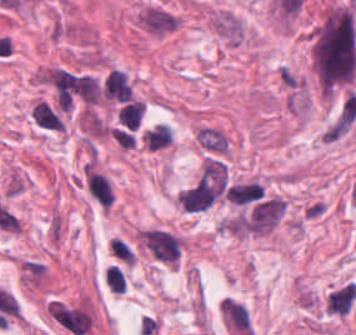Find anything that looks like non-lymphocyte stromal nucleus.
<instances>
[{"label":"non-lymphocyte stromal nucleus","instance_id":"obj_1","mask_svg":"<svg viewBox=\"0 0 356 335\" xmlns=\"http://www.w3.org/2000/svg\"><path fill=\"white\" fill-rule=\"evenodd\" d=\"M228 187L223 161L209 158L183 189L179 203L186 212H203L212 207Z\"/></svg>","mask_w":356,"mask_h":335},{"label":"non-lymphocyte stromal nucleus","instance_id":"obj_2","mask_svg":"<svg viewBox=\"0 0 356 335\" xmlns=\"http://www.w3.org/2000/svg\"><path fill=\"white\" fill-rule=\"evenodd\" d=\"M137 21L139 28L162 38L178 29L182 19L177 12L159 3H145L138 10Z\"/></svg>","mask_w":356,"mask_h":335},{"label":"non-lymphocyte stromal nucleus","instance_id":"obj_3","mask_svg":"<svg viewBox=\"0 0 356 335\" xmlns=\"http://www.w3.org/2000/svg\"><path fill=\"white\" fill-rule=\"evenodd\" d=\"M144 248L161 263L173 264L180 258L179 237L164 228L146 231Z\"/></svg>","mask_w":356,"mask_h":335},{"label":"non-lymphocyte stromal nucleus","instance_id":"obj_4","mask_svg":"<svg viewBox=\"0 0 356 335\" xmlns=\"http://www.w3.org/2000/svg\"><path fill=\"white\" fill-rule=\"evenodd\" d=\"M284 212V201L269 198L258 205L242 222V227L254 234H263L272 229Z\"/></svg>","mask_w":356,"mask_h":335},{"label":"non-lymphocyte stromal nucleus","instance_id":"obj_5","mask_svg":"<svg viewBox=\"0 0 356 335\" xmlns=\"http://www.w3.org/2000/svg\"><path fill=\"white\" fill-rule=\"evenodd\" d=\"M49 308L55 320L73 335H83L89 330L90 315L83 311L59 301H52Z\"/></svg>","mask_w":356,"mask_h":335},{"label":"non-lymphocyte stromal nucleus","instance_id":"obj_6","mask_svg":"<svg viewBox=\"0 0 356 335\" xmlns=\"http://www.w3.org/2000/svg\"><path fill=\"white\" fill-rule=\"evenodd\" d=\"M264 188L257 182L234 183L226 193L229 201L238 204H247L259 198H262Z\"/></svg>","mask_w":356,"mask_h":335},{"label":"non-lymphocyte stromal nucleus","instance_id":"obj_7","mask_svg":"<svg viewBox=\"0 0 356 335\" xmlns=\"http://www.w3.org/2000/svg\"><path fill=\"white\" fill-rule=\"evenodd\" d=\"M198 140L204 147L224 152L228 149L227 137L220 129L206 126L198 132Z\"/></svg>","mask_w":356,"mask_h":335},{"label":"non-lymphocyte stromal nucleus","instance_id":"obj_8","mask_svg":"<svg viewBox=\"0 0 356 335\" xmlns=\"http://www.w3.org/2000/svg\"><path fill=\"white\" fill-rule=\"evenodd\" d=\"M147 148L156 149L172 142V136L168 124L158 123L144 134Z\"/></svg>","mask_w":356,"mask_h":335}]
</instances>
